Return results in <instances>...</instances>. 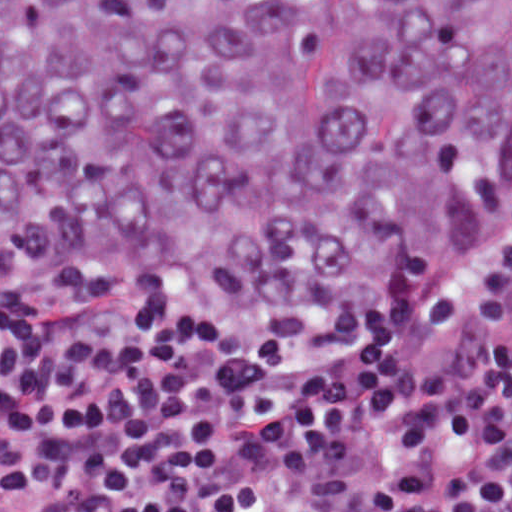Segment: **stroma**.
Segmentation results:
<instances>
[{
    "mask_svg": "<svg viewBox=\"0 0 512 512\" xmlns=\"http://www.w3.org/2000/svg\"><path fill=\"white\" fill-rule=\"evenodd\" d=\"M511 248L512 208L501 227L489 265L471 292L452 306L448 312L433 321L418 336L400 346L392 348L374 357L367 362L398 357L445 337L450 331L462 323V321L485 295L489 287L501 272ZM23 296H26V294H0V302L12 301Z\"/></svg>",
    "mask_w": 512,
    "mask_h": 512,
    "instance_id": "35a3bbf8",
    "label": "stroma"
}]
</instances>
